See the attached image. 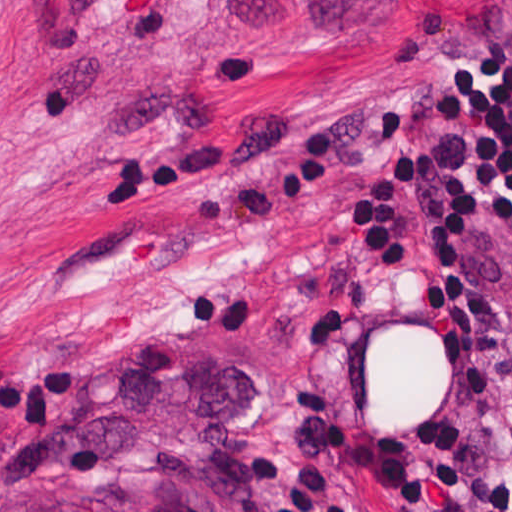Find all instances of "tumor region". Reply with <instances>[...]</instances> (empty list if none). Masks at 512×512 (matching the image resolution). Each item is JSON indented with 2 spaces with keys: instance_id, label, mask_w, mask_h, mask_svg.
<instances>
[{
  "instance_id": "obj_1",
  "label": "tumor region",
  "mask_w": 512,
  "mask_h": 512,
  "mask_svg": "<svg viewBox=\"0 0 512 512\" xmlns=\"http://www.w3.org/2000/svg\"><path fill=\"white\" fill-rule=\"evenodd\" d=\"M256 379L251 359L166 328L75 368L67 412L5 476L0 512H274L225 455L222 421Z\"/></svg>"
}]
</instances>
